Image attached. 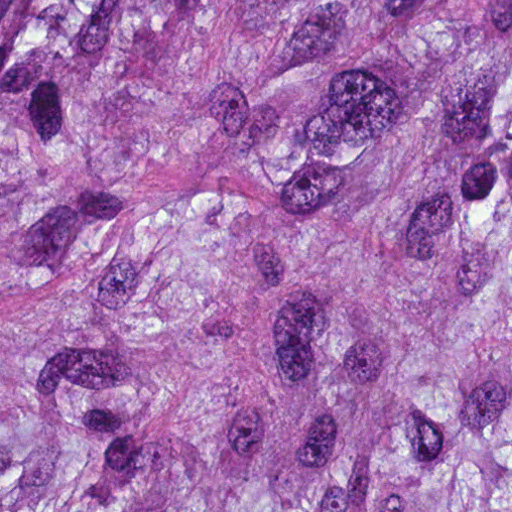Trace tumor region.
I'll list each match as a JSON object with an SVG mask.
<instances>
[{"label":"tumor region","instance_id":"obj_1","mask_svg":"<svg viewBox=\"0 0 512 512\" xmlns=\"http://www.w3.org/2000/svg\"><path fill=\"white\" fill-rule=\"evenodd\" d=\"M1 512H512V0H1Z\"/></svg>","mask_w":512,"mask_h":512}]
</instances>
